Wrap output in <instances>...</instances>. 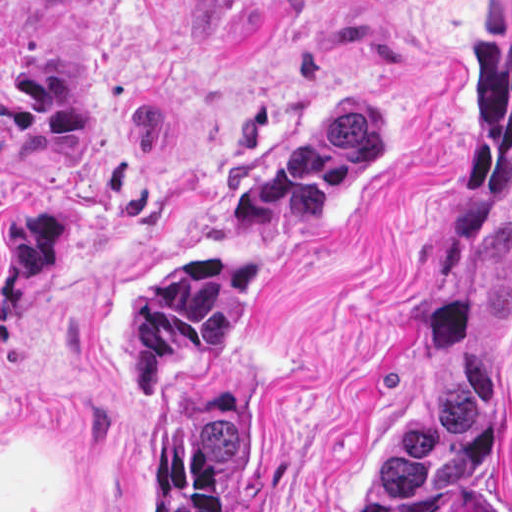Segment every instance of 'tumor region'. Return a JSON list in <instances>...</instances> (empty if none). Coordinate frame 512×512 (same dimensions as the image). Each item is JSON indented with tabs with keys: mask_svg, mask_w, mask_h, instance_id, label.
Masks as SVG:
<instances>
[{
	"mask_svg": "<svg viewBox=\"0 0 512 512\" xmlns=\"http://www.w3.org/2000/svg\"><path fill=\"white\" fill-rule=\"evenodd\" d=\"M387 156V103H355L298 138L237 208L323 217ZM267 282V259L227 246L155 265L124 288L127 365L155 395L166 512H233L239 395L214 348ZM512 329V213L457 229L421 285L393 430L360 462L347 512H468L495 451Z\"/></svg>",
	"mask_w": 512,
	"mask_h": 512,
	"instance_id": "obj_1",
	"label": "tumor region"
}]
</instances>
